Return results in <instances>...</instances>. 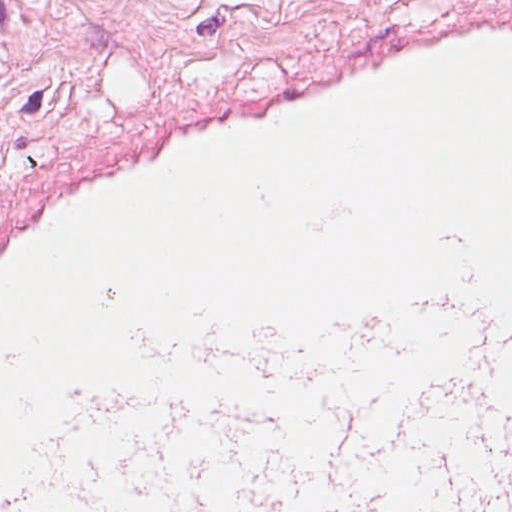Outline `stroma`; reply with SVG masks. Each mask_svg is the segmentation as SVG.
Masks as SVG:
<instances>
[{
    "instance_id": "obj_1",
    "label": "stroma",
    "mask_w": 512,
    "mask_h": 512,
    "mask_svg": "<svg viewBox=\"0 0 512 512\" xmlns=\"http://www.w3.org/2000/svg\"><path fill=\"white\" fill-rule=\"evenodd\" d=\"M493 5L512 0H310L298 54L449 10Z\"/></svg>"
}]
</instances>
